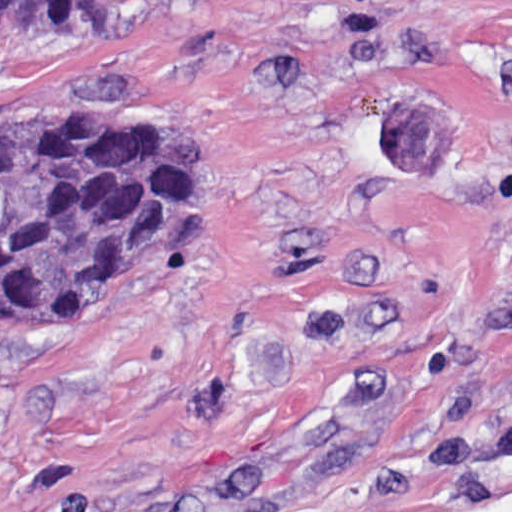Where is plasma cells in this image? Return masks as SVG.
<instances>
[{
  "label": "plasma cells",
  "instance_id": "1",
  "mask_svg": "<svg viewBox=\"0 0 512 512\" xmlns=\"http://www.w3.org/2000/svg\"><path fill=\"white\" fill-rule=\"evenodd\" d=\"M486 316L498 329L512 332V302H498L491 304L486 310Z\"/></svg>",
  "mask_w": 512,
  "mask_h": 512
}]
</instances>
